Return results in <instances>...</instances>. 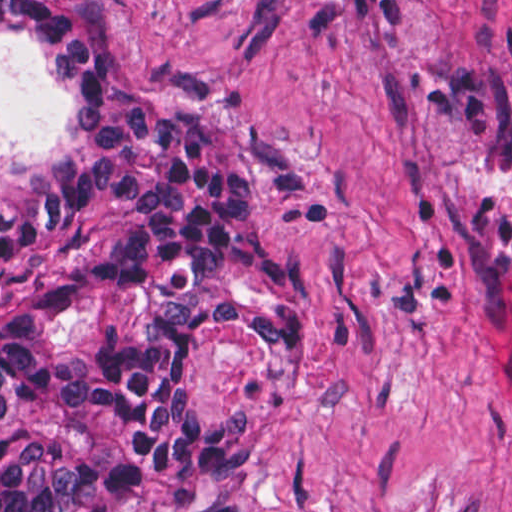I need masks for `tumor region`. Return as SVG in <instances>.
Returning <instances> with one entry per match:
<instances>
[{"mask_svg":"<svg viewBox=\"0 0 512 512\" xmlns=\"http://www.w3.org/2000/svg\"><path fill=\"white\" fill-rule=\"evenodd\" d=\"M0 39L73 128L0 184V512H246L249 427L206 423L188 355L328 332L268 226L296 144L259 113L168 107L75 0H0Z\"/></svg>","mask_w":512,"mask_h":512,"instance_id":"1","label":"tumor region"}]
</instances>
